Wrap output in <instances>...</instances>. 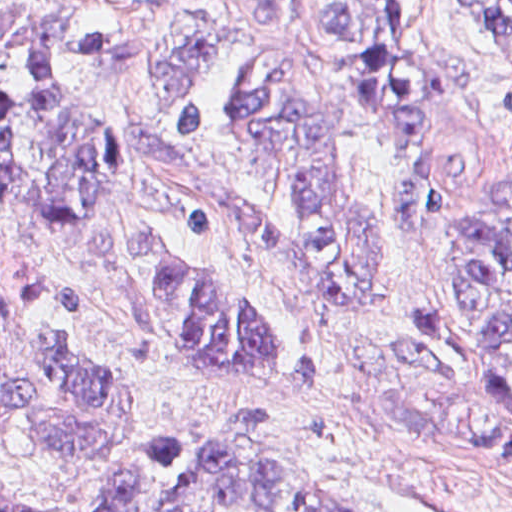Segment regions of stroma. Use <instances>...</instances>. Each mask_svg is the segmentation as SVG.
I'll list each match as a JSON object with an SVG mask.
<instances>
[{
  "instance_id": "35a3bbf8",
  "label": "stroma",
  "mask_w": 512,
  "mask_h": 512,
  "mask_svg": "<svg viewBox=\"0 0 512 512\" xmlns=\"http://www.w3.org/2000/svg\"><path fill=\"white\" fill-rule=\"evenodd\" d=\"M331 1L296 0L289 27L262 28L244 22L231 0H0L1 12H55L73 29L66 73L124 164L121 197L104 216L128 231L162 233L224 278L258 322L279 333L313 335L324 361V383L314 395L202 375L145 329L135 299L101 262L88 222L57 226L0 201V385L23 381L21 343L32 325L71 316L93 331L113 379L150 397L107 457L90 464L61 466L33 437L12 436L0 451V497L90 507L153 446L223 418L234 396L274 410L271 423L248 428L250 438L295 460L341 507L512 512V454L400 420L389 394L404 367L396 324L432 299L452 213L473 208L512 168V42L485 5L406 0L413 53L457 56L467 64L466 100L435 115L424 134L442 177L434 223L400 227L393 148L362 109L342 120L347 184L380 248L376 318L309 297L300 268H289L253 237L222 225L206 231L185 225L184 206L209 199L293 234L305 229L262 158L232 140L180 139L182 105L165 104L169 95L155 82V70L196 32H224L283 54L313 39L317 17Z\"/></svg>"
}]
</instances>
